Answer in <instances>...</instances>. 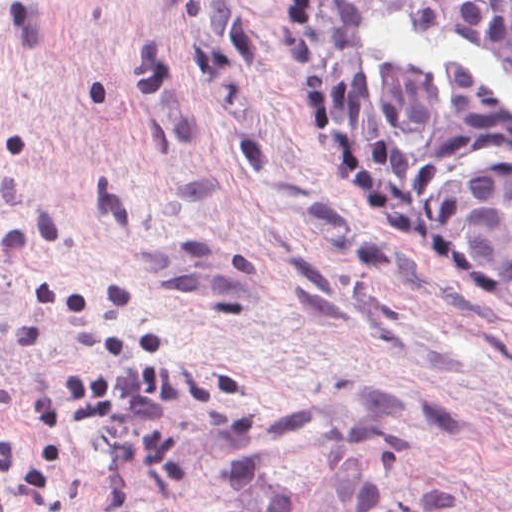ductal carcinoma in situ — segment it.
I'll return each instance as SVG.
<instances>
[{"instance_id": "1", "label": "ductal carcinoma in situ", "mask_w": 512, "mask_h": 512, "mask_svg": "<svg viewBox=\"0 0 512 512\" xmlns=\"http://www.w3.org/2000/svg\"><path fill=\"white\" fill-rule=\"evenodd\" d=\"M293 103L318 153L434 250L512 296V105L458 64L362 69L389 16L489 47L512 68V0H289Z\"/></svg>"}]
</instances>
